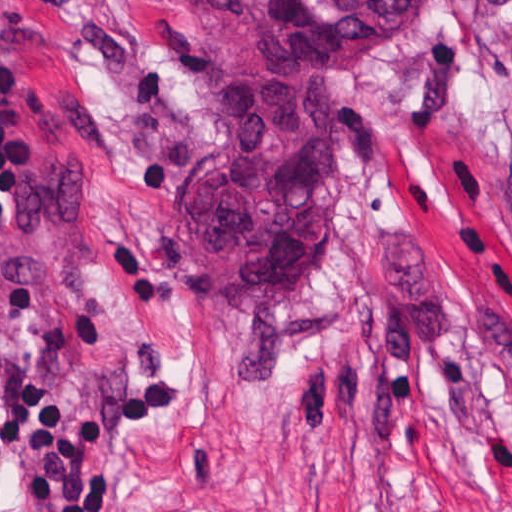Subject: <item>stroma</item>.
Listing matches in <instances>:
<instances>
[{
	"label": "stroma",
	"mask_w": 512,
	"mask_h": 512,
	"mask_svg": "<svg viewBox=\"0 0 512 512\" xmlns=\"http://www.w3.org/2000/svg\"><path fill=\"white\" fill-rule=\"evenodd\" d=\"M0 56V358L175 386L109 512H512V0L358 53L331 259L268 300H216L173 221L217 121L186 0H0Z\"/></svg>",
	"instance_id": "1"
}]
</instances>
